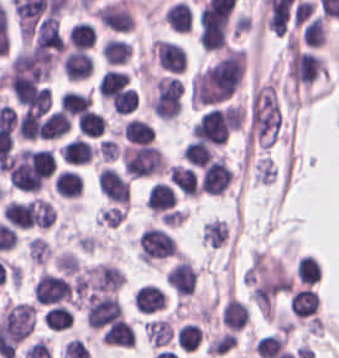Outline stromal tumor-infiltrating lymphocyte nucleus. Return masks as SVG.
<instances>
[{"label":"stromal tumor-infiltrating lymphocyte nucleus","instance_id":"stromal-tumor-infiltrating-lymphocyte-nucleus-16","mask_svg":"<svg viewBox=\"0 0 339 358\" xmlns=\"http://www.w3.org/2000/svg\"><path fill=\"white\" fill-rule=\"evenodd\" d=\"M176 193L168 182H154L148 196L146 205L153 212L169 209L175 203Z\"/></svg>","mask_w":339,"mask_h":358},{"label":"stromal tumor-infiltrating lymphocyte nucleus","instance_id":"stromal-tumor-infiltrating-lymphocyte-nucleus-36","mask_svg":"<svg viewBox=\"0 0 339 358\" xmlns=\"http://www.w3.org/2000/svg\"><path fill=\"white\" fill-rule=\"evenodd\" d=\"M28 258L37 264H42L48 257L51 249L49 242L40 235H33L26 244Z\"/></svg>","mask_w":339,"mask_h":358},{"label":"stromal tumor-infiltrating lymphocyte nucleus","instance_id":"stromal-tumor-infiltrating-lymphocyte-nucleus-35","mask_svg":"<svg viewBox=\"0 0 339 358\" xmlns=\"http://www.w3.org/2000/svg\"><path fill=\"white\" fill-rule=\"evenodd\" d=\"M202 338L201 327L197 322H184L177 331L178 343L186 351H194Z\"/></svg>","mask_w":339,"mask_h":358},{"label":"stromal tumor-infiltrating lymphocyte nucleus","instance_id":"stromal-tumor-infiltrating-lymphocyte-nucleus-17","mask_svg":"<svg viewBox=\"0 0 339 358\" xmlns=\"http://www.w3.org/2000/svg\"><path fill=\"white\" fill-rule=\"evenodd\" d=\"M71 124L69 117L60 109L45 115L39 128L40 139H57Z\"/></svg>","mask_w":339,"mask_h":358},{"label":"stromal tumor-infiltrating lymphocyte nucleus","instance_id":"stromal-tumor-infiltrating-lymphocyte-nucleus-26","mask_svg":"<svg viewBox=\"0 0 339 358\" xmlns=\"http://www.w3.org/2000/svg\"><path fill=\"white\" fill-rule=\"evenodd\" d=\"M73 313L70 307L55 304L46 310L45 326L53 331H61L71 326Z\"/></svg>","mask_w":339,"mask_h":358},{"label":"stromal tumor-infiltrating lymphocyte nucleus","instance_id":"stromal-tumor-infiltrating-lymphocyte-nucleus-19","mask_svg":"<svg viewBox=\"0 0 339 358\" xmlns=\"http://www.w3.org/2000/svg\"><path fill=\"white\" fill-rule=\"evenodd\" d=\"M121 132L127 142H151L154 137L153 126L148 120L133 116L124 122Z\"/></svg>","mask_w":339,"mask_h":358},{"label":"stromal tumor-infiltrating lymphocyte nucleus","instance_id":"stromal-tumor-infiltrating-lymphocyte-nucleus-13","mask_svg":"<svg viewBox=\"0 0 339 358\" xmlns=\"http://www.w3.org/2000/svg\"><path fill=\"white\" fill-rule=\"evenodd\" d=\"M193 16L194 13L192 7L185 0H178L167 7L163 18L173 30L189 32Z\"/></svg>","mask_w":339,"mask_h":358},{"label":"stromal tumor-infiltrating lymphocyte nucleus","instance_id":"stromal-tumor-infiltrating-lymphocyte-nucleus-9","mask_svg":"<svg viewBox=\"0 0 339 358\" xmlns=\"http://www.w3.org/2000/svg\"><path fill=\"white\" fill-rule=\"evenodd\" d=\"M168 177L188 197H199L201 187L194 167L170 164L168 166Z\"/></svg>","mask_w":339,"mask_h":358},{"label":"stromal tumor-infiltrating lymphocyte nucleus","instance_id":"stromal-tumor-infiltrating-lymphocyte-nucleus-25","mask_svg":"<svg viewBox=\"0 0 339 358\" xmlns=\"http://www.w3.org/2000/svg\"><path fill=\"white\" fill-rule=\"evenodd\" d=\"M214 150L211 145L198 139L186 142L184 147V157L193 166H205L213 156Z\"/></svg>","mask_w":339,"mask_h":358},{"label":"stromal tumor-infiltrating lymphocyte nucleus","instance_id":"stromal-tumor-infiltrating-lymphocyte-nucleus-1","mask_svg":"<svg viewBox=\"0 0 339 358\" xmlns=\"http://www.w3.org/2000/svg\"><path fill=\"white\" fill-rule=\"evenodd\" d=\"M87 321L95 327L127 325L128 320L116 294L97 293L86 305Z\"/></svg>","mask_w":339,"mask_h":358},{"label":"stromal tumor-infiltrating lymphocyte nucleus","instance_id":"stromal-tumor-infiltrating-lymphocyte-nucleus-24","mask_svg":"<svg viewBox=\"0 0 339 358\" xmlns=\"http://www.w3.org/2000/svg\"><path fill=\"white\" fill-rule=\"evenodd\" d=\"M76 124L79 132L98 137L104 132V115L88 108L76 118Z\"/></svg>","mask_w":339,"mask_h":358},{"label":"stromal tumor-infiltrating lymphocyte nucleus","instance_id":"stromal-tumor-infiltrating-lymphocyte-nucleus-22","mask_svg":"<svg viewBox=\"0 0 339 358\" xmlns=\"http://www.w3.org/2000/svg\"><path fill=\"white\" fill-rule=\"evenodd\" d=\"M127 72L107 69L97 81L96 89L103 99H111L124 85Z\"/></svg>","mask_w":339,"mask_h":358},{"label":"stromal tumor-infiltrating lymphocyte nucleus","instance_id":"stromal-tumor-infiltrating-lymphocyte-nucleus-2","mask_svg":"<svg viewBox=\"0 0 339 358\" xmlns=\"http://www.w3.org/2000/svg\"><path fill=\"white\" fill-rule=\"evenodd\" d=\"M137 248L143 262L149 264L176 254L178 245L169 232L152 226L142 230Z\"/></svg>","mask_w":339,"mask_h":358},{"label":"stromal tumor-infiltrating lymphocyte nucleus","instance_id":"stromal-tumor-infiltrating-lymphocyte-nucleus-8","mask_svg":"<svg viewBox=\"0 0 339 358\" xmlns=\"http://www.w3.org/2000/svg\"><path fill=\"white\" fill-rule=\"evenodd\" d=\"M61 68L70 80L87 78L93 69V58L82 49L71 48L66 52Z\"/></svg>","mask_w":339,"mask_h":358},{"label":"stromal tumor-infiltrating lymphocyte nucleus","instance_id":"stromal-tumor-infiltrating-lymphocyte-nucleus-28","mask_svg":"<svg viewBox=\"0 0 339 358\" xmlns=\"http://www.w3.org/2000/svg\"><path fill=\"white\" fill-rule=\"evenodd\" d=\"M96 33L89 22L77 21L68 33V41L72 47L89 48L95 41Z\"/></svg>","mask_w":339,"mask_h":358},{"label":"stromal tumor-infiltrating lymphocyte nucleus","instance_id":"stromal-tumor-infiltrating-lymphocyte-nucleus-14","mask_svg":"<svg viewBox=\"0 0 339 358\" xmlns=\"http://www.w3.org/2000/svg\"><path fill=\"white\" fill-rule=\"evenodd\" d=\"M61 156L71 165H82L91 160L94 146L81 136H74L60 150Z\"/></svg>","mask_w":339,"mask_h":358},{"label":"stromal tumor-infiltrating lymphocyte nucleus","instance_id":"stromal-tumor-infiltrating-lymphocyte-nucleus-34","mask_svg":"<svg viewBox=\"0 0 339 358\" xmlns=\"http://www.w3.org/2000/svg\"><path fill=\"white\" fill-rule=\"evenodd\" d=\"M228 235V226L223 219H214L204 223L201 238L210 246H221Z\"/></svg>","mask_w":339,"mask_h":358},{"label":"stromal tumor-infiltrating lymphocyte nucleus","instance_id":"stromal-tumor-infiltrating-lymphocyte-nucleus-5","mask_svg":"<svg viewBox=\"0 0 339 358\" xmlns=\"http://www.w3.org/2000/svg\"><path fill=\"white\" fill-rule=\"evenodd\" d=\"M232 178L225 155H217L205 165L200 187L211 194H222Z\"/></svg>","mask_w":339,"mask_h":358},{"label":"stromal tumor-infiltrating lymphocyte nucleus","instance_id":"stromal-tumor-infiltrating-lymphocyte-nucleus-30","mask_svg":"<svg viewBox=\"0 0 339 358\" xmlns=\"http://www.w3.org/2000/svg\"><path fill=\"white\" fill-rule=\"evenodd\" d=\"M102 342L114 344L116 346H131L134 343L133 327L129 324L118 323L107 327L101 335Z\"/></svg>","mask_w":339,"mask_h":358},{"label":"stromal tumor-infiltrating lymphocyte nucleus","instance_id":"stromal-tumor-infiltrating-lymphocyte-nucleus-21","mask_svg":"<svg viewBox=\"0 0 339 358\" xmlns=\"http://www.w3.org/2000/svg\"><path fill=\"white\" fill-rule=\"evenodd\" d=\"M2 217L15 228H29L31 225L30 212L26 201L10 199L2 207Z\"/></svg>","mask_w":339,"mask_h":358},{"label":"stromal tumor-infiltrating lymphocyte nucleus","instance_id":"stromal-tumor-infiltrating-lymphocyte-nucleus-18","mask_svg":"<svg viewBox=\"0 0 339 358\" xmlns=\"http://www.w3.org/2000/svg\"><path fill=\"white\" fill-rule=\"evenodd\" d=\"M26 206L33 225L46 229L56 222V211L50 201L36 196Z\"/></svg>","mask_w":339,"mask_h":358},{"label":"stromal tumor-infiltrating lymphocyte nucleus","instance_id":"stromal-tumor-infiltrating-lymphocyte-nucleus-12","mask_svg":"<svg viewBox=\"0 0 339 358\" xmlns=\"http://www.w3.org/2000/svg\"><path fill=\"white\" fill-rule=\"evenodd\" d=\"M319 306V297L315 289L310 286L298 288L289 300V308L294 316H314Z\"/></svg>","mask_w":339,"mask_h":358},{"label":"stromal tumor-infiltrating lymphocyte nucleus","instance_id":"stromal-tumor-infiltrating-lymphocyte-nucleus-20","mask_svg":"<svg viewBox=\"0 0 339 358\" xmlns=\"http://www.w3.org/2000/svg\"><path fill=\"white\" fill-rule=\"evenodd\" d=\"M83 187V178L75 170L62 169L55 177V191L65 198H77Z\"/></svg>","mask_w":339,"mask_h":358},{"label":"stromal tumor-infiltrating lymphocyte nucleus","instance_id":"stromal-tumor-infiltrating-lymphocyte-nucleus-29","mask_svg":"<svg viewBox=\"0 0 339 358\" xmlns=\"http://www.w3.org/2000/svg\"><path fill=\"white\" fill-rule=\"evenodd\" d=\"M255 350L260 358H276L284 352V337L268 333L256 340Z\"/></svg>","mask_w":339,"mask_h":358},{"label":"stromal tumor-infiltrating lymphocyte nucleus","instance_id":"stromal-tumor-infiltrating-lymphocyte-nucleus-27","mask_svg":"<svg viewBox=\"0 0 339 358\" xmlns=\"http://www.w3.org/2000/svg\"><path fill=\"white\" fill-rule=\"evenodd\" d=\"M130 45L120 38L107 37L103 43L102 57L110 64L122 63L129 59Z\"/></svg>","mask_w":339,"mask_h":358},{"label":"stromal tumor-infiltrating lymphocyte nucleus","instance_id":"stromal-tumor-infiltrating-lymphocyte-nucleus-7","mask_svg":"<svg viewBox=\"0 0 339 358\" xmlns=\"http://www.w3.org/2000/svg\"><path fill=\"white\" fill-rule=\"evenodd\" d=\"M170 287L181 295L194 294L197 280L195 266L187 258H180L166 273Z\"/></svg>","mask_w":339,"mask_h":358},{"label":"stromal tumor-infiltrating lymphocyte nucleus","instance_id":"stromal-tumor-infiltrating-lymphocyte-nucleus-32","mask_svg":"<svg viewBox=\"0 0 339 358\" xmlns=\"http://www.w3.org/2000/svg\"><path fill=\"white\" fill-rule=\"evenodd\" d=\"M326 26L321 15L307 20L302 30V39L307 46H320L324 42Z\"/></svg>","mask_w":339,"mask_h":358},{"label":"stromal tumor-infiltrating lymphocyte nucleus","instance_id":"stromal-tumor-infiltrating-lymphocyte-nucleus-6","mask_svg":"<svg viewBox=\"0 0 339 358\" xmlns=\"http://www.w3.org/2000/svg\"><path fill=\"white\" fill-rule=\"evenodd\" d=\"M152 53L159 64L172 73H180L186 65V54L179 43L154 38Z\"/></svg>","mask_w":339,"mask_h":358},{"label":"stromal tumor-infiltrating lymphocyte nucleus","instance_id":"stromal-tumor-infiltrating-lymphocyte-nucleus-11","mask_svg":"<svg viewBox=\"0 0 339 358\" xmlns=\"http://www.w3.org/2000/svg\"><path fill=\"white\" fill-rule=\"evenodd\" d=\"M134 303L142 311L153 313L164 308L166 304L165 291L156 284L144 283L138 287Z\"/></svg>","mask_w":339,"mask_h":358},{"label":"stromal tumor-infiltrating lymphocyte nucleus","instance_id":"stromal-tumor-infiltrating-lymphocyte-nucleus-4","mask_svg":"<svg viewBox=\"0 0 339 358\" xmlns=\"http://www.w3.org/2000/svg\"><path fill=\"white\" fill-rule=\"evenodd\" d=\"M31 291L36 302H62L67 300L71 292L70 281L43 270L32 284Z\"/></svg>","mask_w":339,"mask_h":358},{"label":"stromal tumor-infiltrating lymphocyte nucleus","instance_id":"stromal-tumor-infiltrating-lymphocyte-nucleus-10","mask_svg":"<svg viewBox=\"0 0 339 358\" xmlns=\"http://www.w3.org/2000/svg\"><path fill=\"white\" fill-rule=\"evenodd\" d=\"M221 320L231 331H240L249 321V311L243 300L229 295L221 310Z\"/></svg>","mask_w":339,"mask_h":358},{"label":"stromal tumor-infiltrating lymphocyte nucleus","instance_id":"stromal-tumor-infiltrating-lymphocyte-nucleus-31","mask_svg":"<svg viewBox=\"0 0 339 358\" xmlns=\"http://www.w3.org/2000/svg\"><path fill=\"white\" fill-rule=\"evenodd\" d=\"M296 275L303 285H312L321 275V265L316 257L304 254L296 266Z\"/></svg>","mask_w":339,"mask_h":358},{"label":"stromal tumor-infiltrating lymphocyte nucleus","instance_id":"stromal-tumor-infiltrating-lymphocyte-nucleus-23","mask_svg":"<svg viewBox=\"0 0 339 358\" xmlns=\"http://www.w3.org/2000/svg\"><path fill=\"white\" fill-rule=\"evenodd\" d=\"M92 103L88 92L78 89H65L60 98V109L69 114H78Z\"/></svg>","mask_w":339,"mask_h":358},{"label":"stromal tumor-infiltrating lymphocyte nucleus","instance_id":"stromal-tumor-infiltrating-lymphocyte-nucleus-15","mask_svg":"<svg viewBox=\"0 0 339 358\" xmlns=\"http://www.w3.org/2000/svg\"><path fill=\"white\" fill-rule=\"evenodd\" d=\"M174 334L171 321L164 317L147 319L144 325V336L152 346H165L170 343Z\"/></svg>","mask_w":339,"mask_h":358},{"label":"stromal tumor-infiltrating lymphocyte nucleus","instance_id":"stromal-tumor-infiltrating-lymphocyte-nucleus-3","mask_svg":"<svg viewBox=\"0 0 339 358\" xmlns=\"http://www.w3.org/2000/svg\"><path fill=\"white\" fill-rule=\"evenodd\" d=\"M0 315L19 342L35 327L36 305L25 301H6Z\"/></svg>","mask_w":339,"mask_h":358},{"label":"stromal tumor-infiltrating lymphocyte nucleus","instance_id":"stromal-tumor-infiltrating-lymphocyte-nucleus-33","mask_svg":"<svg viewBox=\"0 0 339 358\" xmlns=\"http://www.w3.org/2000/svg\"><path fill=\"white\" fill-rule=\"evenodd\" d=\"M111 103L113 110L127 114L138 104V92L132 85H124L113 95Z\"/></svg>","mask_w":339,"mask_h":358}]
</instances>
